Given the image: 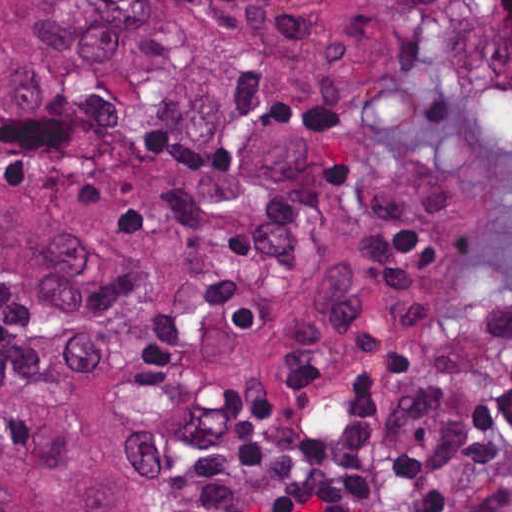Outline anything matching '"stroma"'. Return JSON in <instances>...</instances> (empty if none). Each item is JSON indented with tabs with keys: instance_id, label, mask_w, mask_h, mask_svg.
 <instances>
[{
	"instance_id": "35a3bbf8",
	"label": "stroma",
	"mask_w": 512,
	"mask_h": 512,
	"mask_svg": "<svg viewBox=\"0 0 512 512\" xmlns=\"http://www.w3.org/2000/svg\"><path fill=\"white\" fill-rule=\"evenodd\" d=\"M427 383L471 385L486 401L495 394L492 400L512 394V200L498 205L495 251L488 267L448 325L404 375L330 415L262 473L204 489L174 512L221 511L327 451L371 409ZM399 512L422 511L413 500H405Z\"/></svg>"
}]
</instances>
